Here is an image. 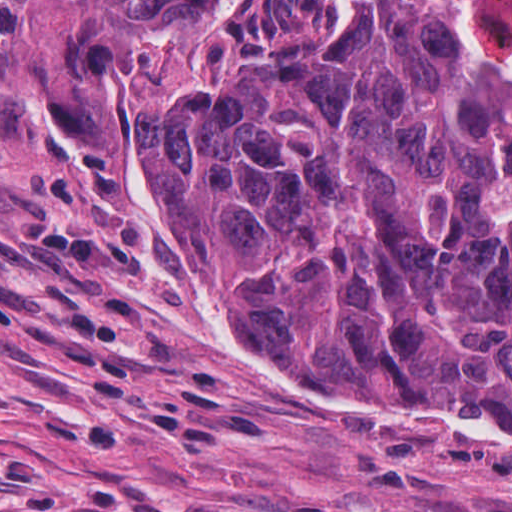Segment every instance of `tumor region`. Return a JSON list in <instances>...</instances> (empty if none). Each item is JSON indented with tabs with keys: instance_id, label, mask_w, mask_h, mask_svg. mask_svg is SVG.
Here are the masks:
<instances>
[{
	"instance_id": "obj_1",
	"label": "tumor region",
	"mask_w": 512,
	"mask_h": 512,
	"mask_svg": "<svg viewBox=\"0 0 512 512\" xmlns=\"http://www.w3.org/2000/svg\"><path fill=\"white\" fill-rule=\"evenodd\" d=\"M52 87L265 362L512 427V0H69Z\"/></svg>"
}]
</instances>
